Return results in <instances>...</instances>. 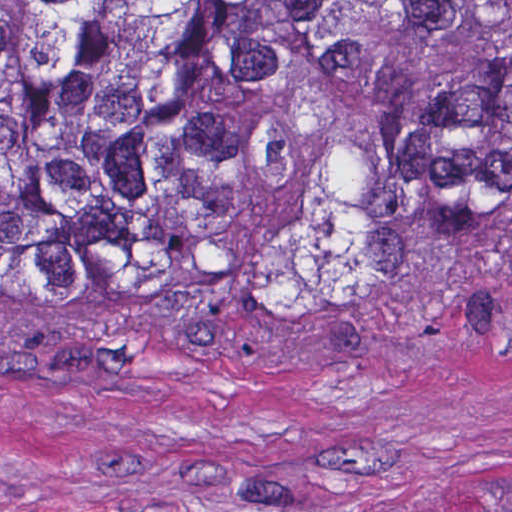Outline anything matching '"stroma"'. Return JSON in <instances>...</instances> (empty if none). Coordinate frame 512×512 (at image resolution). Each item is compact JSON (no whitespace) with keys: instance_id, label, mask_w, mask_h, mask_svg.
<instances>
[{"instance_id":"stroma-1","label":"stroma","mask_w":512,"mask_h":512,"mask_svg":"<svg viewBox=\"0 0 512 512\" xmlns=\"http://www.w3.org/2000/svg\"><path fill=\"white\" fill-rule=\"evenodd\" d=\"M0 512H512V291L276 331L0 301Z\"/></svg>"}]
</instances>
